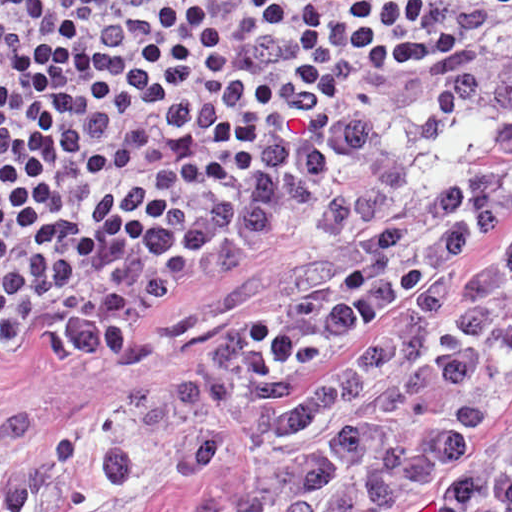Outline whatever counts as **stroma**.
<instances>
[{"label": "stroma", "instance_id": "1", "mask_svg": "<svg viewBox=\"0 0 512 512\" xmlns=\"http://www.w3.org/2000/svg\"><path fill=\"white\" fill-rule=\"evenodd\" d=\"M512 37V16L472 48L365 67L218 173L106 228L28 275L1 309L0 512L99 378L150 380L216 353L326 283L334 248L307 228L320 199L381 141L398 104ZM512 242V199L473 245L461 280ZM266 487L257 419L194 477L148 476L127 512H241Z\"/></svg>", "mask_w": 512, "mask_h": 512}]
</instances>
